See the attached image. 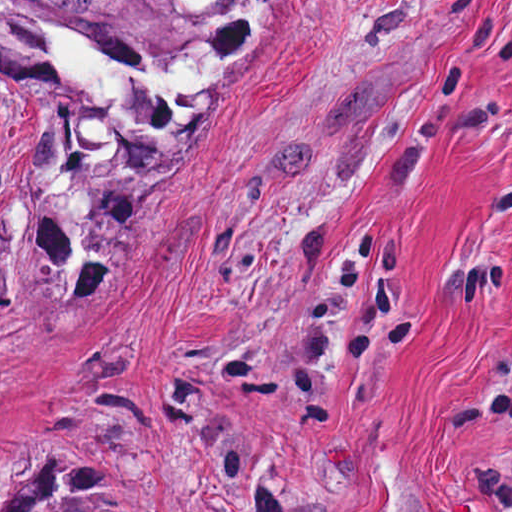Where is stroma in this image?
<instances>
[{"instance_id":"35a3bbf8","label":"stroma","mask_w":512,"mask_h":512,"mask_svg":"<svg viewBox=\"0 0 512 512\" xmlns=\"http://www.w3.org/2000/svg\"><path fill=\"white\" fill-rule=\"evenodd\" d=\"M35 455L142 512H512V0L0 62V487Z\"/></svg>"}]
</instances>
